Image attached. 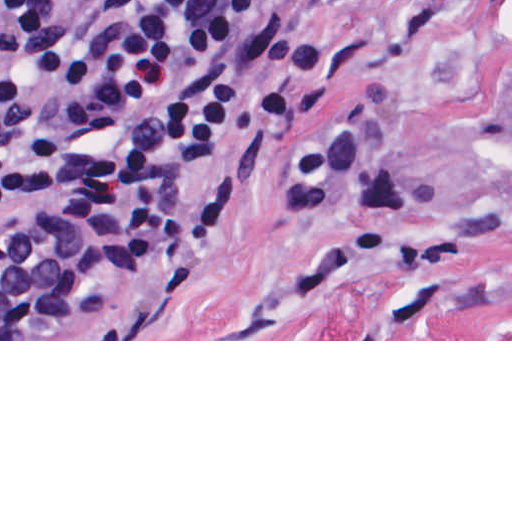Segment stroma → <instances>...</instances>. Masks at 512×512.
Listing matches in <instances>:
<instances>
[{"label":"stroma","instance_id":"1","mask_svg":"<svg viewBox=\"0 0 512 512\" xmlns=\"http://www.w3.org/2000/svg\"><path fill=\"white\" fill-rule=\"evenodd\" d=\"M512 0H244L239 107L197 162L178 221L227 199L217 249L168 261L123 339L512 341V146L478 111L488 41ZM296 24L326 85L269 140L264 86Z\"/></svg>","mask_w":512,"mask_h":512}]
</instances>
